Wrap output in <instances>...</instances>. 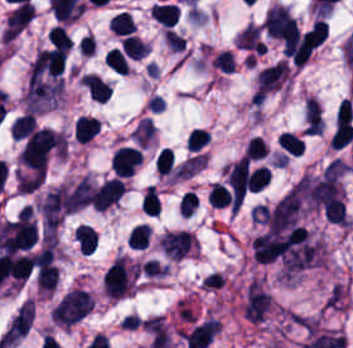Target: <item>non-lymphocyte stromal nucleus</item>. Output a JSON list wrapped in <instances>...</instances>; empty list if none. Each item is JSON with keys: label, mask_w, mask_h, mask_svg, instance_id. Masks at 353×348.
<instances>
[{"label": "non-lymphocyte stromal nucleus", "mask_w": 353, "mask_h": 348, "mask_svg": "<svg viewBox=\"0 0 353 348\" xmlns=\"http://www.w3.org/2000/svg\"><path fill=\"white\" fill-rule=\"evenodd\" d=\"M93 307L92 296L83 290L69 291L52 310V320L72 325L83 318Z\"/></svg>", "instance_id": "obj_1"}, {"label": "non-lymphocyte stromal nucleus", "mask_w": 353, "mask_h": 348, "mask_svg": "<svg viewBox=\"0 0 353 348\" xmlns=\"http://www.w3.org/2000/svg\"><path fill=\"white\" fill-rule=\"evenodd\" d=\"M68 191L64 186L49 190L39 203V212L45 231L54 232L63 219Z\"/></svg>", "instance_id": "obj_2"}, {"label": "non-lymphocyte stromal nucleus", "mask_w": 353, "mask_h": 348, "mask_svg": "<svg viewBox=\"0 0 353 348\" xmlns=\"http://www.w3.org/2000/svg\"><path fill=\"white\" fill-rule=\"evenodd\" d=\"M33 308L34 302L26 299L15 311L0 338V344L2 346L9 348L27 332L32 320Z\"/></svg>", "instance_id": "obj_3"}, {"label": "non-lymphocyte stromal nucleus", "mask_w": 353, "mask_h": 348, "mask_svg": "<svg viewBox=\"0 0 353 348\" xmlns=\"http://www.w3.org/2000/svg\"><path fill=\"white\" fill-rule=\"evenodd\" d=\"M296 26L291 13L280 5H274L264 15V30L266 35L284 39Z\"/></svg>", "instance_id": "obj_4"}, {"label": "non-lymphocyte stromal nucleus", "mask_w": 353, "mask_h": 348, "mask_svg": "<svg viewBox=\"0 0 353 348\" xmlns=\"http://www.w3.org/2000/svg\"><path fill=\"white\" fill-rule=\"evenodd\" d=\"M288 76V69L284 61H277L260 69L256 92L264 94L275 90Z\"/></svg>", "instance_id": "obj_5"}, {"label": "non-lymphocyte stromal nucleus", "mask_w": 353, "mask_h": 348, "mask_svg": "<svg viewBox=\"0 0 353 348\" xmlns=\"http://www.w3.org/2000/svg\"><path fill=\"white\" fill-rule=\"evenodd\" d=\"M123 183L118 177H111L95 189L93 207L105 209L117 201L122 192Z\"/></svg>", "instance_id": "obj_6"}, {"label": "non-lymphocyte stromal nucleus", "mask_w": 353, "mask_h": 348, "mask_svg": "<svg viewBox=\"0 0 353 348\" xmlns=\"http://www.w3.org/2000/svg\"><path fill=\"white\" fill-rule=\"evenodd\" d=\"M92 197V185L87 177L83 175L67 193L63 201L64 209L75 211L88 203Z\"/></svg>", "instance_id": "obj_7"}, {"label": "non-lymphocyte stromal nucleus", "mask_w": 353, "mask_h": 348, "mask_svg": "<svg viewBox=\"0 0 353 348\" xmlns=\"http://www.w3.org/2000/svg\"><path fill=\"white\" fill-rule=\"evenodd\" d=\"M236 47L256 53H264L261 31L258 25L249 23L236 37Z\"/></svg>", "instance_id": "obj_8"}]
</instances>
